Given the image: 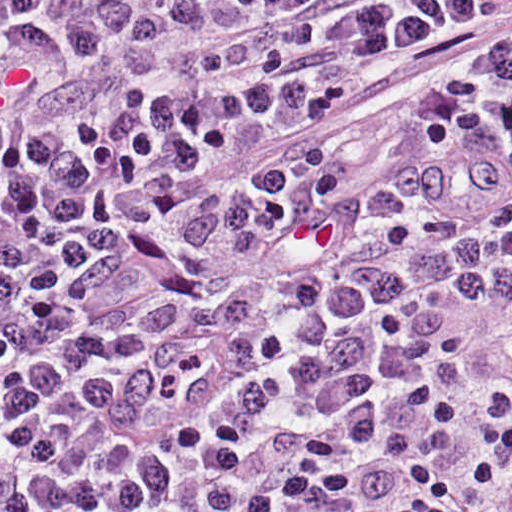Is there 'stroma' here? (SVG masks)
Returning a JSON list of instances; mask_svg holds the SVG:
<instances>
[{
	"instance_id": "35a3bbf8",
	"label": "stroma",
	"mask_w": 512,
	"mask_h": 512,
	"mask_svg": "<svg viewBox=\"0 0 512 512\" xmlns=\"http://www.w3.org/2000/svg\"><path fill=\"white\" fill-rule=\"evenodd\" d=\"M477 512H512V469L487 485Z\"/></svg>"
}]
</instances>
